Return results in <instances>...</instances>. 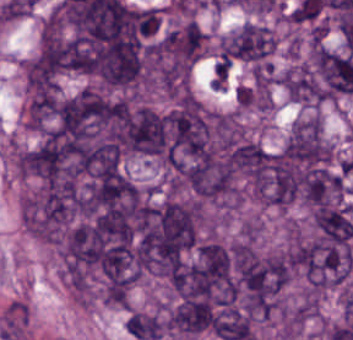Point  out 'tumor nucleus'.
Listing matches in <instances>:
<instances>
[{
    "label": "tumor nucleus",
    "mask_w": 353,
    "mask_h": 340,
    "mask_svg": "<svg viewBox=\"0 0 353 340\" xmlns=\"http://www.w3.org/2000/svg\"><path fill=\"white\" fill-rule=\"evenodd\" d=\"M263 223L258 216H251L241 222L239 233L241 238L247 240H258L262 236Z\"/></svg>",
    "instance_id": "obj_5"
},
{
    "label": "tumor nucleus",
    "mask_w": 353,
    "mask_h": 340,
    "mask_svg": "<svg viewBox=\"0 0 353 340\" xmlns=\"http://www.w3.org/2000/svg\"><path fill=\"white\" fill-rule=\"evenodd\" d=\"M62 116L59 94L35 97L25 104V120L35 130H54Z\"/></svg>",
    "instance_id": "obj_1"
},
{
    "label": "tumor nucleus",
    "mask_w": 353,
    "mask_h": 340,
    "mask_svg": "<svg viewBox=\"0 0 353 340\" xmlns=\"http://www.w3.org/2000/svg\"><path fill=\"white\" fill-rule=\"evenodd\" d=\"M10 153L15 174L21 178L40 176L37 146L12 141Z\"/></svg>",
    "instance_id": "obj_3"
},
{
    "label": "tumor nucleus",
    "mask_w": 353,
    "mask_h": 340,
    "mask_svg": "<svg viewBox=\"0 0 353 340\" xmlns=\"http://www.w3.org/2000/svg\"><path fill=\"white\" fill-rule=\"evenodd\" d=\"M166 318L156 309L132 308L125 319V327L134 337L157 340L164 335Z\"/></svg>",
    "instance_id": "obj_2"
},
{
    "label": "tumor nucleus",
    "mask_w": 353,
    "mask_h": 340,
    "mask_svg": "<svg viewBox=\"0 0 353 340\" xmlns=\"http://www.w3.org/2000/svg\"><path fill=\"white\" fill-rule=\"evenodd\" d=\"M29 320V308L20 301H13L3 312L2 329H24Z\"/></svg>",
    "instance_id": "obj_4"
}]
</instances>
